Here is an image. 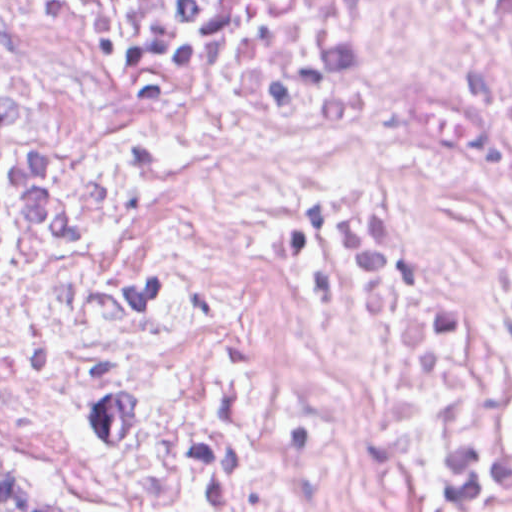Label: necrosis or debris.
<instances>
[{
  "mask_svg": "<svg viewBox=\"0 0 512 512\" xmlns=\"http://www.w3.org/2000/svg\"><path fill=\"white\" fill-rule=\"evenodd\" d=\"M111 512H512V0H0V444Z\"/></svg>",
  "mask_w": 512,
  "mask_h": 512,
  "instance_id": "4bbe7bcc",
  "label": "necrosis or debris"
}]
</instances>
